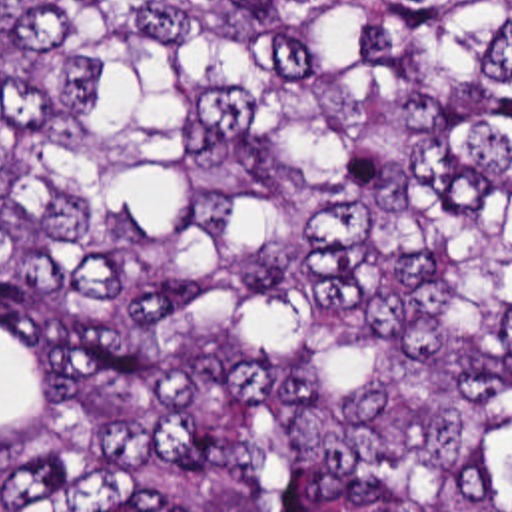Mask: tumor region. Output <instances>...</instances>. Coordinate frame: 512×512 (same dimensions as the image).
Listing matches in <instances>:
<instances>
[{
  "label": "tumor region",
  "mask_w": 512,
  "mask_h": 512,
  "mask_svg": "<svg viewBox=\"0 0 512 512\" xmlns=\"http://www.w3.org/2000/svg\"><path fill=\"white\" fill-rule=\"evenodd\" d=\"M0 512H512V0H0Z\"/></svg>",
  "instance_id": "1"
}]
</instances>
